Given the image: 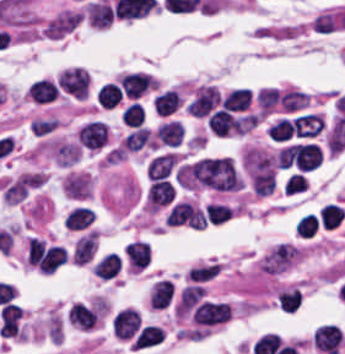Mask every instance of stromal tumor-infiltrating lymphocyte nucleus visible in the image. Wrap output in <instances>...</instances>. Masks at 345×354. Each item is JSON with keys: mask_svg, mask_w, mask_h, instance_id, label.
<instances>
[{"mask_svg": "<svg viewBox=\"0 0 345 354\" xmlns=\"http://www.w3.org/2000/svg\"><path fill=\"white\" fill-rule=\"evenodd\" d=\"M120 87L126 96L137 98L154 88V79L135 71L121 75Z\"/></svg>", "mask_w": 345, "mask_h": 354, "instance_id": "stromal-tumor-infiltrating-lymphocyte-nucleus-7", "label": "stromal tumor-infiltrating lymphocyte nucleus"}, {"mask_svg": "<svg viewBox=\"0 0 345 354\" xmlns=\"http://www.w3.org/2000/svg\"><path fill=\"white\" fill-rule=\"evenodd\" d=\"M206 125L216 136L239 133V119L223 108H216L207 117Z\"/></svg>", "mask_w": 345, "mask_h": 354, "instance_id": "stromal-tumor-infiltrating-lymphocyte-nucleus-6", "label": "stromal tumor-infiltrating lymphocyte nucleus"}, {"mask_svg": "<svg viewBox=\"0 0 345 354\" xmlns=\"http://www.w3.org/2000/svg\"><path fill=\"white\" fill-rule=\"evenodd\" d=\"M219 271L218 264L191 267L187 273L188 281L202 282L212 278Z\"/></svg>", "mask_w": 345, "mask_h": 354, "instance_id": "stromal-tumor-infiltrating-lymphocyte-nucleus-27", "label": "stromal tumor-infiltrating lymphocyte nucleus"}, {"mask_svg": "<svg viewBox=\"0 0 345 354\" xmlns=\"http://www.w3.org/2000/svg\"><path fill=\"white\" fill-rule=\"evenodd\" d=\"M202 291L203 288L200 285H187L182 289L175 305V314L184 317L198 301Z\"/></svg>", "mask_w": 345, "mask_h": 354, "instance_id": "stromal-tumor-infiltrating-lymphocyte-nucleus-12", "label": "stromal tumor-infiltrating lymphocyte nucleus"}, {"mask_svg": "<svg viewBox=\"0 0 345 354\" xmlns=\"http://www.w3.org/2000/svg\"><path fill=\"white\" fill-rule=\"evenodd\" d=\"M306 185L307 180L303 175H300L298 173H291L284 186V194L292 195L299 192H303Z\"/></svg>", "mask_w": 345, "mask_h": 354, "instance_id": "stromal-tumor-infiltrating-lymphocyte-nucleus-28", "label": "stromal tumor-infiltrating lymphocyte nucleus"}, {"mask_svg": "<svg viewBox=\"0 0 345 354\" xmlns=\"http://www.w3.org/2000/svg\"><path fill=\"white\" fill-rule=\"evenodd\" d=\"M320 224L324 228H334L341 223L345 216V209L337 204L325 203L318 211Z\"/></svg>", "mask_w": 345, "mask_h": 354, "instance_id": "stromal-tumor-infiltrating-lymphocyte-nucleus-20", "label": "stromal tumor-infiltrating lymphocyte nucleus"}, {"mask_svg": "<svg viewBox=\"0 0 345 354\" xmlns=\"http://www.w3.org/2000/svg\"><path fill=\"white\" fill-rule=\"evenodd\" d=\"M55 84L61 95L74 99L88 97L91 79L88 71L81 67H67L55 76Z\"/></svg>", "mask_w": 345, "mask_h": 354, "instance_id": "stromal-tumor-infiltrating-lymphocyte-nucleus-1", "label": "stromal tumor-infiltrating lymphocyte nucleus"}, {"mask_svg": "<svg viewBox=\"0 0 345 354\" xmlns=\"http://www.w3.org/2000/svg\"><path fill=\"white\" fill-rule=\"evenodd\" d=\"M179 95L174 89H167L156 95L152 102L153 111L161 114L172 113L179 103Z\"/></svg>", "mask_w": 345, "mask_h": 354, "instance_id": "stromal-tumor-infiltrating-lymphocyte-nucleus-22", "label": "stromal tumor-infiltrating lymphocyte nucleus"}, {"mask_svg": "<svg viewBox=\"0 0 345 354\" xmlns=\"http://www.w3.org/2000/svg\"><path fill=\"white\" fill-rule=\"evenodd\" d=\"M152 138L146 127H138L128 132L120 142V146L128 151H136L143 148L151 147Z\"/></svg>", "mask_w": 345, "mask_h": 354, "instance_id": "stromal-tumor-infiltrating-lymphocyte-nucleus-11", "label": "stromal tumor-infiltrating lymphocyte nucleus"}, {"mask_svg": "<svg viewBox=\"0 0 345 354\" xmlns=\"http://www.w3.org/2000/svg\"><path fill=\"white\" fill-rule=\"evenodd\" d=\"M205 212L210 225L216 226L228 220L232 214L230 208L221 203H207L205 205Z\"/></svg>", "mask_w": 345, "mask_h": 354, "instance_id": "stromal-tumor-infiltrating-lymphocyte-nucleus-25", "label": "stromal tumor-infiltrating lymphocyte nucleus"}, {"mask_svg": "<svg viewBox=\"0 0 345 354\" xmlns=\"http://www.w3.org/2000/svg\"><path fill=\"white\" fill-rule=\"evenodd\" d=\"M143 119L142 106L137 102H130L122 111L120 120L126 127H140Z\"/></svg>", "mask_w": 345, "mask_h": 354, "instance_id": "stromal-tumor-infiltrating-lymphocyte-nucleus-23", "label": "stromal tumor-infiltrating lymphocyte nucleus"}, {"mask_svg": "<svg viewBox=\"0 0 345 354\" xmlns=\"http://www.w3.org/2000/svg\"><path fill=\"white\" fill-rule=\"evenodd\" d=\"M120 268V259L118 254L107 252L93 266V274L99 278H113Z\"/></svg>", "mask_w": 345, "mask_h": 354, "instance_id": "stromal-tumor-infiltrating-lymphocyte-nucleus-14", "label": "stromal tumor-infiltrating lymphocyte nucleus"}, {"mask_svg": "<svg viewBox=\"0 0 345 354\" xmlns=\"http://www.w3.org/2000/svg\"><path fill=\"white\" fill-rule=\"evenodd\" d=\"M93 217L94 214L91 210L83 207H76L66 216L64 226L69 230H82L91 224Z\"/></svg>", "mask_w": 345, "mask_h": 354, "instance_id": "stromal-tumor-infiltrating-lymphocyte-nucleus-21", "label": "stromal tumor-infiltrating lymphocyte nucleus"}, {"mask_svg": "<svg viewBox=\"0 0 345 354\" xmlns=\"http://www.w3.org/2000/svg\"><path fill=\"white\" fill-rule=\"evenodd\" d=\"M251 98L250 90L236 87L222 98L221 107L232 111H244Z\"/></svg>", "mask_w": 345, "mask_h": 354, "instance_id": "stromal-tumor-infiltrating-lymphocyte-nucleus-16", "label": "stromal tumor-infiltrating lymphocyte nucleus"}, {"mask_svg": "<svg viewBox=\"0 0 345 354\" xmlns=\"http://www.w3.org/2000/svg\"><path fill=\"white\" fill-rule=\"evenodd\" d=\"M317 228L318 216L314 213H307L296 221L295 231L301 238H310Z\"/></svg>", "mask_w": 345, "mask_h": 354, "instance_id": "stromal-tumor-infiltrating-lymphocyte-nucleus-24", "label": "stromal tumor-infiltrating lymphocyte nucleus"}, {"mask_svg": "<svg viewBox=\"0 0 345 354\" xmlns=\"http://www.w3.org/2000/svg\"><path fill=\"white\" fill-rule=\"evenodd\" d=\"M155 134L161 144L176 146L183 135V128L172 119L159 123Z\"/></svg>", "mask_w": 345, "mask_h": 354, "instance_id": "stromal-tumor-infiltrating-lymphocyte-nucleus-15", "label": "stromal tumor-infiltrating lymphocyte nucleus"}, {"mask_svg": "<svg viewBox=\"0 0 345 354\" xmlns=\"http://www.w3.org/2000/svg\"><path fill=\"white\" fill-rule=\"evenodd\" d=\"M265 131L274 141L288 139L292 133L289 120L282 117L270 123Z\"/></svg>", "mask_w": 345, "mask_h": 354, "instance_id": "stromal-tumor-infiltrating-lymphocyte-nucleus-26", "label": "stromal tumor-infiltrating lymphocyte nucleus"}, {"mask_svg": "<svg viewBox=\"0 0 345 354\" xmlns=\"http://www.w3.org/2000/svg\"><path fill=\"white\" fill-rule=\"evenodd\" d=\"M259 90L255 94V101L258 104Z\"/></svg>", "mask_w": 345, "mask_h": 354, "instance_id": "stromal-tumor-infiltrating-lymphocyte-nucleus-29", "label": "stromal tumor-infiltrating lymphocyte nucleus"}, {"mask_svg": "<svg viewBox=\"0 0 345 354\" xmlns=\"http://www.w3.org/2000/svg\"><path fill=\"white\" fill-rule=\"evenodd\" d=\"M107 128L104 123L97 120H90L76 130V140L85 147L96 149L106 140Z\"/></svg>", "mask_w": 345, "mask_h": 354, "instance_id": "stromal-tumor-infiltrating-lymphocyte-nucleus-5", "label": "stromal tumor-infiltrating lymphocyte nucleus"}, {"mask_svg": "<svg viewBox=\"0 0 345 354\" xmlns=\"http://www.w3.org/2000/svg\"><path fill=\"white\" fill-rule=\"evenodd\" d=\"M170 280L160 279L151 284L147 299V306L152 308H165L172 292Z\"/></svg>", "mask_w": 345, "mask_h": 354, "instance_id": "stromal-tumor-infiltrating-lymphocyte-nucleus-10", "label": "stromal tumor-infiltrating lymphocyte nucleus"}, {"mask_svg": "<svg viewBox=\"0 0 345 354\" xmlns=\"http://www.w3.org/2000/svg\"><path fill=\"white\" fill-rule=\"evenodd\" d=\"M219 99L215 86L202 85L185 105V112L196 117L210 113Z\"/></svg>", "mask_w": 345, "mask_h": 354, "instance_id": "stromal-tumor-infiltrating-lymphocyte-nucleus-3", "label": "stromal tumor-infiltrating lymphocyte nucleus"}, {"mask_svg": "<svg viewBox=\"0 0 345 354\" xmlns=\"http://www.w3.org/2000/svg\"><path fill=\"white\" fill-rule=\"evenodd\" d=\"M87 19L93 27L105 28L112 20L111 6L103 0H90L86 4Z\"/></svg>", "mask_w": 345, "mask_h": 354, "instance_id": "stromal-tumor-infiltrating-lymphocyte-nucleus-9", "label": "stromal tumor-infiltrating lymphocyte nucleus"}, {"mask_svg": "<svg viewBox=\"0 0 345 354\" xmlns=\"http://www.w3.org/2000/svg\"><path fill=\"white\" fill-rule=\"evenodd\" d=\"M121 260L124 269L139 272L147 267L149 250L146 241L130 240L123 248Z\"/></svg>", "mask_w": 345, "mask_h": 354, "instance_id": "stromal-tumor-infiltrating-lymphocyte-nucleus-4", "label": "stromal tumor-infiltrating lymphocyte nucleus"}, {"mask_svg": "<svg viewBox=\"0 0 345 354\" xmlns=\"http://www.w3.org/2000/svg\"><path fill=\"white\" fill-rule=\"evenodd\" d=\"M176 160V155L166 153L152 157L147 164L146 173L150 178H163Z\"/></svg>", "mask_w": 345, "mask_h": 354, "instance_id": "stromal-tumor-infiltrating-lymphocyte-nucleus-19", "label": "stromal tumor-infiltrating lymphocyte nucleus"}, {"mask_svg": "<svg viewBox=\"0 0 345 354\" xmlns=\"http://www.w3.org/2000/svg\"><path fill=\"white\" fill-rule=\"evenodd\" d=\"M122 91L119 85L107 82L99 85L94 97L103 108H110L119 103Z\"/></svg>", "mask_w": 345, "mask_h": 354, "instance_id": "stromal-tumor-infiltrating-lymphocyte-nucleus-18", "label": "stromal tumor-infiltrating lymphocyte nucleus"}, {"mask_svg": "<svg viewBox=\"0 0 345 354\" xmlns=\"http://www.w3.org/2000/svg\"><path fill=\"white\" fill-rule=\"evenodd\" d=\"M26 92L32 101L46 102L55 98L57 89L54 83L42 78L33 80Z\"/></svg>", "mask_w": 345, "mask_h": 354, "instance_id": "stromal-tumor-infiltrating-lymphocyte-nucleus-13", "label": "stromal tumor-infiltrating lymphocyte nucleus"}, {"mask_svg": "<svg viewBox=\"0 0 345 354\" xmlns=\"http://www.w3.org/2000/svg\"><path fill=\"white\" fill-rule=\"evenodd\" d=\"M276 309L281 313H293L300 302L298 288L286 286L274 299Z\"/></svg>", "mask_w": 345, "mask_h": 354, "instance_id": "stromal-tumor-infiltrating-lymphocyte-nucleus-17", "label": "stromal tumor-infiltrating lymphocyte nucleus"}, {"mask_svg": "<svg viewBox=\"0 0 345 354\" xmlns=\"http://www.w3.org/2000/svg\"><path fill=\"white\" fill-rule=\"evenodd\" d=\"M191 319L200 327H211L226 323L229 319V307L223 302L202 301L196 305Z\"/></svg>", "mask_w": 345, "mask_h": 354, "instance_id": "stromal-tumor-infiltrating-lymphocyte-nucleus-2", "label": "stromal tumor-infiltrating lymphocyte nucleus"}, {"mask_svg": "<svg viewBox=\"0 0 345 354\" xmlns=\"http://www.w3.org/2000/svg\"><path fill=\"white\" fill-rule=\"evenodd\" d=\"M172 196V186L162 178H155L147 189L146 200L151 209H158L169 204Z\"/></svg>", "mask_w": 345, "mask_h": 354, "instance_id": "stromal-tumor-infiltrating-lymphocyte-nucleus-8", "label": "stromal tumor-infiltrating lymphocyte nucleus"}]
</instances>
